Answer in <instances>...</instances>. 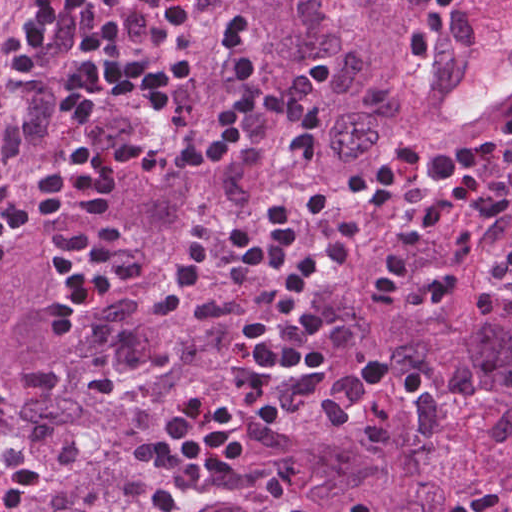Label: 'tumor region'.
I'll use <instances>...</instances> for the list:
<instances>
[{"label":"tumor region","instance_id":"tumor-region-1","mask_svg":"<svg viewBox=\"0 0 512 512\" xmlns=\"http://www.w3.org/2000/svg\"><path fill=\"white\" fill-rule=\"evenodd\" d=\"M424 0H193L183 51L194 81L179 133L214 109L223 67L213 39L232 13L259 29L261 86L228 161L182 185L240 213L289 186L330 198L351 162L427 119L428 76L408 54ZM0 0V198L52 181L71 152L55 98L8 57L30 21ZM45 52L59 59L78 27V0H51ZM106 130L135 135L114 107ZM372 234L311 309L331 375L297 417L250 439L240 463L205 492L165 488L146 446L192 382L233 392L259 280L210 285L166 333L152 323L191 236L170 241L169 201L153 183L121 184L93 225L150 268L143 285L74 319L52 264L51 221L0 259V512H450L456 498L512 485V310L484 286L480 229L422 249L406 290L379 294V265L424 218ZM161 257L158 259L159 254Z\"/></svg>","mask_w":512,"mask_h":512}]
</instances>
